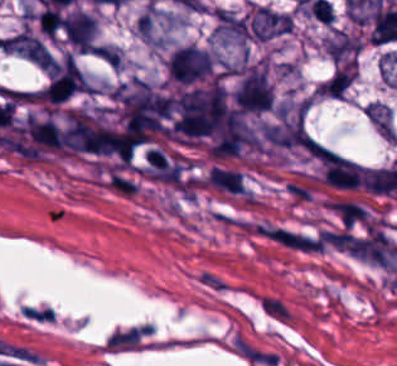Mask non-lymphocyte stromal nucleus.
<instances>
[{"label":"non-lymphocyte stromal nucleus","mask_w":397,"mask_h":366,"mask_svg":"<svg viewBox=\"0 0 397 366\" xmlns=\"http://www.w3.org/2000/svg\"><path fill=\"white\" fill-rule=\"evenodd\" d=\"M258 306L259 308L268 311L280 318H283L287 321H291L293 318V313L286 310L285 308L281 307L280 305L274 303L273 301L269 300L268 298L264 297L263 295H259L258 297Z\"/></svg>","instance_id":"non-lymphocyte-stromal-nucleus-5"},{"label":"non-lymphocyte stromal nucleus","mask_w":397,"mask_h":366,"mask_svg":"<svg viewBox=\"0 0 397 366\" xmlns=\"http://www.w3.org/2000/svg\"><path fill=\"white\" fill-rule=\"evenodd\" d=\"M234 352L257 366H273L277 358V352L243 335H235Z\"/></svg>","instance_id":"non-lymphocyte-stromal-nucleus-2"},{"label":"non-lymphocyte stromal nucleus","mask_w":397,"mask_h":366,"mask_svg":"<svg viewBox=\"0 0 397 366\" xmlns=\"http://www.w3.org/2000/svg\"><path fill=\"white\" fill-rule=\"evenodd\" d=\"M207 183L231 193H245L241 172L235 169L212 167Z\"/></svg>","instance_id":"non-lymphocyte-stromal-nucleus-3"},{"label":"non-lymphocyte stromal nucleus","mask_w":397,"mask_h":366,"mask_svg":"<svg viewBox=\"0 0 397 366\" xmlns=\"http://www.w3.org/2000/svg\"><path fill=\"white\" fill-rule=\"evenodd\" d=\"M149 331V326H135L114 332L106 343L113 348L135 347Z\"/></svg>","instance_id":"non-lymphocyte-stromal-nucleus-4"},{"label":"non-lymphocyte stromal nucleus","mask_w":397,"mask_h":366,"mask_svg":"<svg viewBox=\"0 0 397 366\" xmlns=\"http://www.w3.org/2000/svg\"><path fill=\"white\" fill-rule=\"evenodd\" d=\"M254 230L258 236L287 250L304 251L301 231L274 222H260Z\"/></svg>","instance_id":"non-lymphocyte-stromal-nucleus-1"}]
</instances>
